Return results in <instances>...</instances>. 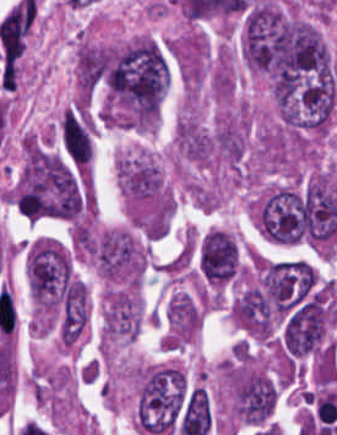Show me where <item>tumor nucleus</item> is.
<instances>
[{
    "instance_id": "2f306a5c",
    "label": "tumor nucleus",
    "mask_w": 337,
    "mask_h": 435,
    "mask_svg": "<svg viewBox=\"0 0 337 435\" xmlns=\"http://www.w3.org/2000/svg\"><path fill=\"white\" fill-rule=\"evenodd\" d=\"M90 254L96 273L105 281L138 278L144 267V255L128 229L101 232Z\"/></svg>"
},
{
    "instance_id": "8643909e",
    "label": "tumor nucleus",
    "mask_w": 337,
    "mask_h": 435,
    "mask_svg": "<svg viewBox=\"0 0 337 435\" xmlns=\"http://www.w3.org/2000/svg\"><path fill=\"white\" fill-rule=\"evenodd\" d=\"M238 255L234 236L216 229L202 240L201 272L209 283L223 284L235 277Z\"/></svg>"
}]
</instances>
